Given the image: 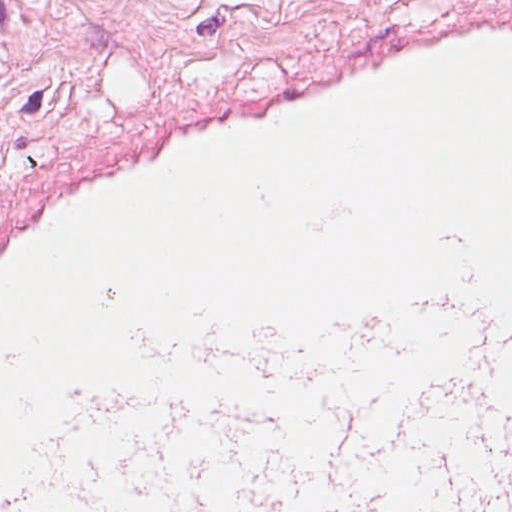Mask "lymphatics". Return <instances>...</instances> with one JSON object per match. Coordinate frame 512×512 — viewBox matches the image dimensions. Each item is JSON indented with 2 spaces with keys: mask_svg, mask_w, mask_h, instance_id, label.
Returning a JSON list of instances; mask_svg holds the SVG:
<instances>
[{
  "mask_svg": "<svg viewBox=\"0 0 512 512\" xmlns=\"http://www.w3.org/2000/svg\"><path fill=\"white\" fill-rule=\"evenodd\" d=\"M439 291L239 335L201 512H512V303L440 240Z\"/></svg>",
  "mask_w": 512,
  "mask_h": 512,
  "instance_id": "788a7518",
  "label": "lymphatics"
}]
</instances>
